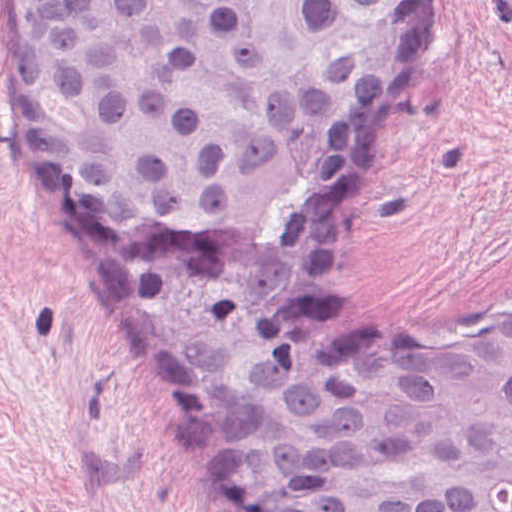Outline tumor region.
<instances>
[{
  "mask_svg": "<svg viewBox=\"0 0 512 512\" xmlns=\"http://www.w3.org/2000/svg\"><path fill=\"white\" fill-rule=\"evenodd\" d=\"M44 136L230 512H512V318L410 339L327 275L415 0H5Z\"/></svg>",
  "mask_w": 512,
  "mask_h": 512,
  "instance_id": "1",
  "label": "tumor region"
}]
</instances>
